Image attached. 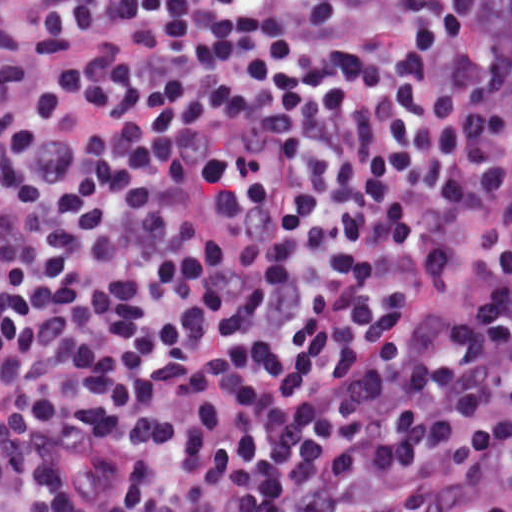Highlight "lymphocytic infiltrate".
Returning <instances> with one entry per match:
<instances>
[{"label":"lymphocytic infiltrate","instance_id":"1","mask_svg":"<svg viewBox=\"0 0 512 512\" xmlns=\"http://www.w3.org/2000/svg\"><path fill=\"white\" fill-rule=\"evenodd\" d=\"M0 512H512V0H0Z\"/></svg>","mask_w":512,"mask_h":512}]
</instances>
